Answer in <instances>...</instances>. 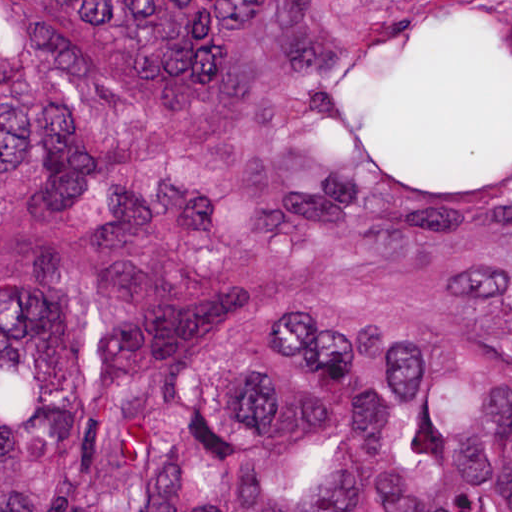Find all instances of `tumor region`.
Segmentation results:
<instances>
[{
    "label": "tumor region",
    "mask_w": 512,
    "mask_h": 512,
    "mask_svg": "<svg viewBox=\"0 0 512 512\" xmlns=\"http://www.w3.org/2000/svg\"><path fill=\"white\" fill-rule=\"evenodd\" d=\"M0 512H512V0H0Z\"/></svg>",
    "instance_id": "obj_1"
}]
</instances>
